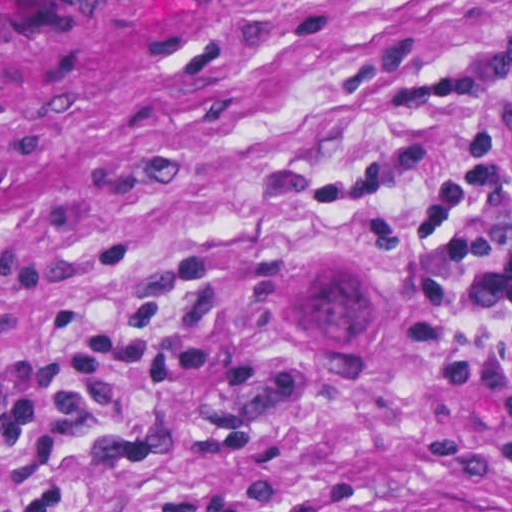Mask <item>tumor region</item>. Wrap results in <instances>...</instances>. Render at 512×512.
Returning <instances> with one entry per match:
<instances>
[{"mask_svg": "<svg viewBox=\"0 0 512 512\" xmlns=\"http://www.w3.org/2000/svg\"><path fill=\"white\" fill-rule=\"evenodd\" d=\"M365 276V275H364ZM367 278V276H365ZM391 309V307H390ZM392 312V310H391ZM393 314V312H392ZM400 358V340L398 344V348L393 357V360L389 366H387L383 371H381L377 376L387 375L395 363ZM375 376V377H377ZM372 376L364 377L371 378ZM359 512H489L485 509L479 508L477 506H391L385 508L364 510Z\"/></svg>", "mask_w": 512, "mask_h": 512, "instance_id": "e687c5a6", "label": "tumor region"}]
</instances>
